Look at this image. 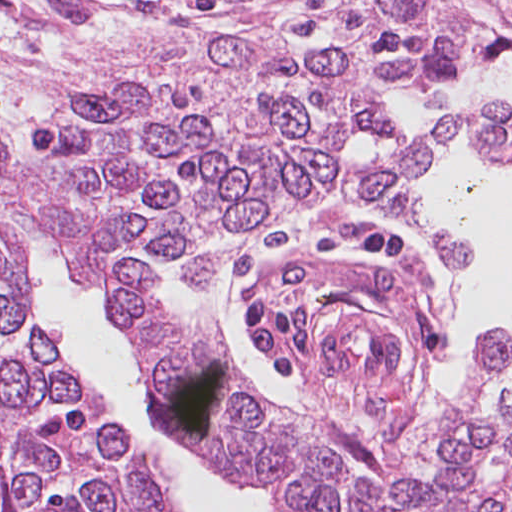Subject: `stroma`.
I'll list each match as a JSON object with an SVG mask.
<instances>
[{
  "instance_id": "obj_1",
  "label": "stroma",
  "mask_w": 512,
  "mask_h": 512,
  "mask_svg": "<svg viewBox=\"0 0 512 512\" xmlns=\"http://www.w3.org/2000/svg\"><path fill=\"white\" fill-rule=\"evenodd\" d=\"M157 15H182L314 48L304 38L286 33L266 0H0V110L15 132L20 135L31 104H42L62 76L127 26ZM486 68L490 67H480L454 82ZM369 81L394 122L383 91ZM430 125L410 134V139ZM458 135L470 142L466 127L421 157L431 153L435 157ZM403 144L398 141L374 154L393 152ZM345 158H349L346 152ZM422 175L409 185V193L424 216L444 232L472 243L468 233L433 210L421 187ZM388 228L412 232L377 208L350 205L337 193L234 255L215 282L236 284L240 300L265 291L277 301L308 308L317 357L299 364L298 376L286 381L303 416L320 433L435 396L429 383L437 373L445 329L438 312L424 301L431 274L428 262L408 248L406 256L387 263L360 259L354 251L367 233ZM14 247L30 261L39 302L128 431L148 446L171 480L199 473L153 425L148 367L104 303L75 283L47 242ZM358 302L380 312L391 327L398 365L386 376H354L321 356L324 330L340 311ZM219 328L235 367L266 397L290 408L241 363Z\"/></svg>"
}]
</instances>
